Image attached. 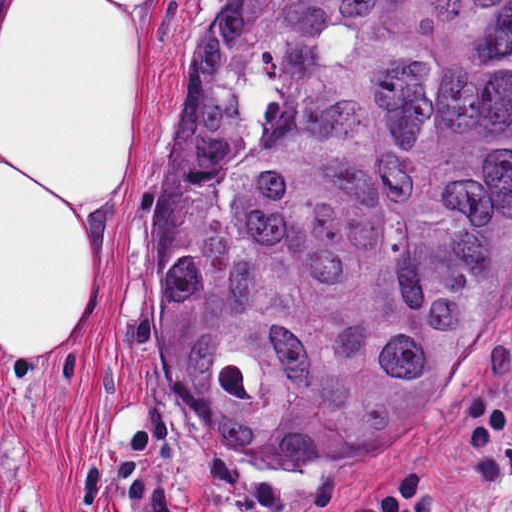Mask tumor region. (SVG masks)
I'll return each instance as SVG.
<instances>
[{
    "label": "tumor region",
    "mask_w": 512,
    "mask_h": 512,
    "mask_svg": "<svg viewBox=\"0 0 512 512\" xmlns=\"http://www.w3.org/2000/svg\"><path fill=\"white\" fill-rule=\"evenodd\" d=\"M512 271V0H227L152 222L162 372L272 464L389 447Z\"/></svg>",
    "instance_id": "obj_1"
}]
</instances>
